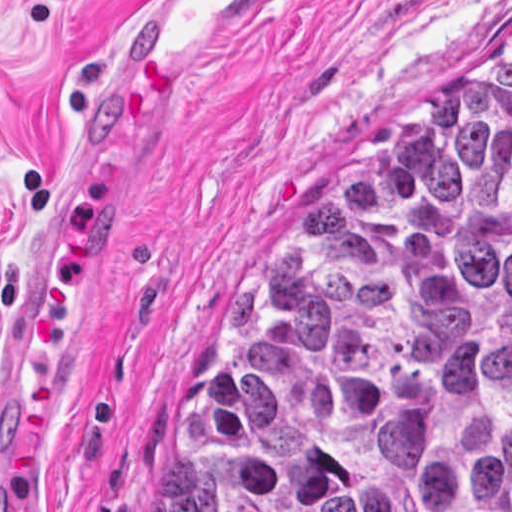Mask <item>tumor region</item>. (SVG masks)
<instances>
[{"label": "tumor region", "mask_w": 512, "mask_h": 512, "mask_svg": "<svg viewBox=\"0 0 512 512\" xmlns=\"http://www.w3.org/2000/svg\"><path fill=\"white\" fill-rule=\"evenodd\" d=\"M132 512H512V47L331 151Z\"/></svg>", "instance_id": "1"}]
</instances>
